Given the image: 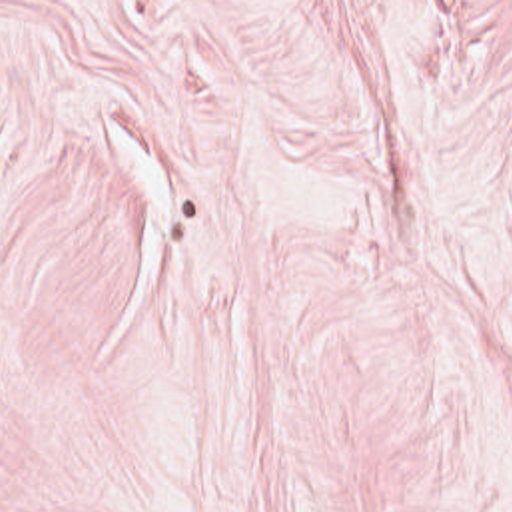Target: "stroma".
Returning a JSON list of instances; mask_svg holds the SVG:
<instances>
[{"label": "stroma", "mask_w": 512, "mask_h": 512, "mask_svg": "<svg viewBox=\"0 0 512 512\" xmlns=\"http://www.w3.org/2000/svg\"><path fill=\"white\" fill-rule=\"evenodd\" d=\"M0 512H512V0H0Z\"/></svg>", "instance_id": "stroma-1"}]
</instances>
